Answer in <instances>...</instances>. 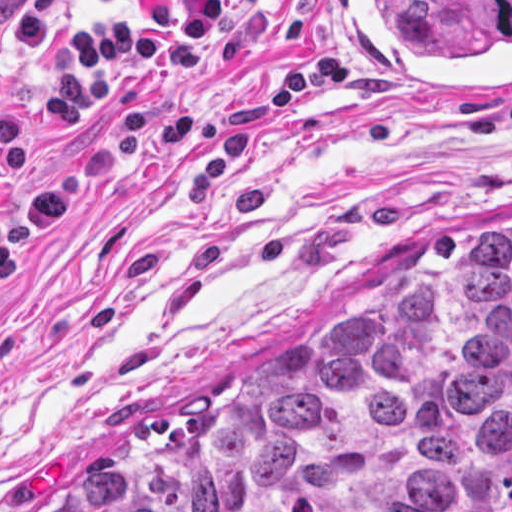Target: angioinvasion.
<instances>
[{
    "mask_svg": "<svg viewBox=\"0 0 512 512\" xmlns=\"http://www.w3.org/2000/svg\"><path fill=\"white\" fill-rule=\"evenodd\" d=\"M352 83L399 97H512V0H333Z\"/></svg>",
    "mask_w": 512,
    "mask_h": 512,
    "instance_id": "1",
    "label": "angioinvasion"
}]
</instances>
